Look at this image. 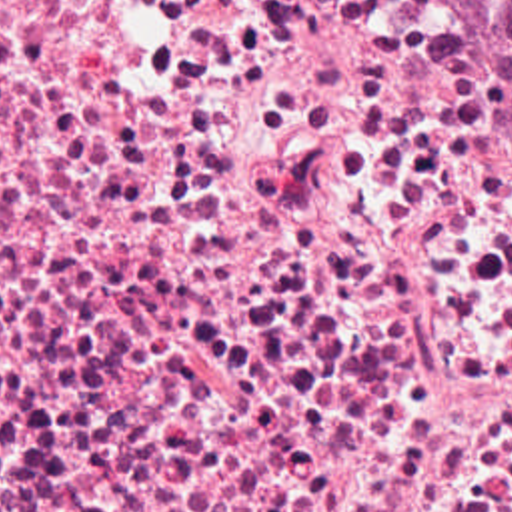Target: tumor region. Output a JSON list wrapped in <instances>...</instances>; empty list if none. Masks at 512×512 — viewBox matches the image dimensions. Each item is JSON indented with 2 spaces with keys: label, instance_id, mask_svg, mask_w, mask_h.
I'll return each instance as SVG.
<instances>
[{
  "label": "tumor region",
  "instance_id": "tumor-region-1",
  "mask_svg": "<svg viewBox=\"0 0 512 512\" xmlns=\"http://www.w3.org/2000/svg\"><path fill=\"white\" fill-rule=\"evenodd\" d=\"M483 64L512 92V0H453Z\"/></svg>",
  "mask_w": 512,
  "mask_h": 512
}]
</instances>
